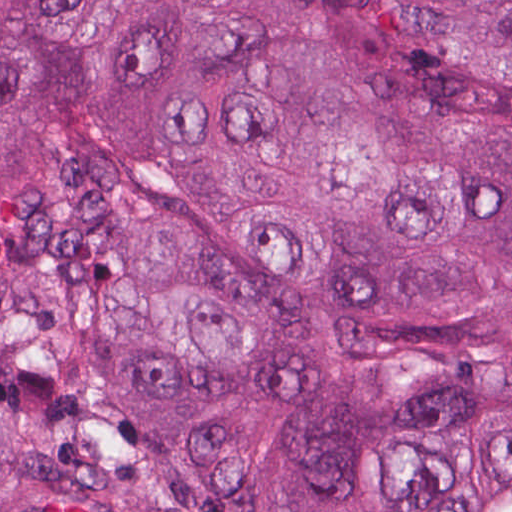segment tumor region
I'll list each match as a JSON object with an SVG mask.
<instances>
[{"label":"tumor region","mask_w":512,"mask_h":512,"mask_svg":"<svg viewBox=\"0 0 512 512\" xmlns=\"http://www.w3.org/2000/svg\"><path fill=\"white\" fill-rule=\"evenodd\" d=\"M0 512H512V0H0Z\"/></svg>","instance_id":"obj_1"}]
</instances>
